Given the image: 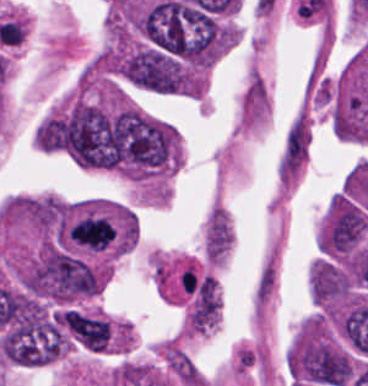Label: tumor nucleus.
Listing matches in <instances>:
<instances>
[{
  "label": "tumor nucleus",
  "instance_id": "obj_1",
  "mask_svg": "<svg viewBox=\"0 0 368 386\" xmlns=\"http://www.w3.org/2000/svg\"><path fill=\"white\" fill-rule=\"evenodd\" d=\"M60 324L66 333L89 352H108L113 324L107 317L75 308L61 310Z\"/></svg>",
  "mask_w": 368,
  "mask_h": 386
},
{
  "label": "tumor nucleus",
  "instance_id": "obj_2",
  "mask_svg": "<svg viewBox=\"0 0 368 386\" xmlns=\"http://www.w3.org/2000/svg\"><path fill=\"white\" fill-rule=\"evenodd\" d=\"M310 286L316 303L331 306L351 292L352 284L343 267L332 260H319L311 266Z\"/></svg>",
  "mask_w": 368,
  "mask_h": 386
}]
</instances>
